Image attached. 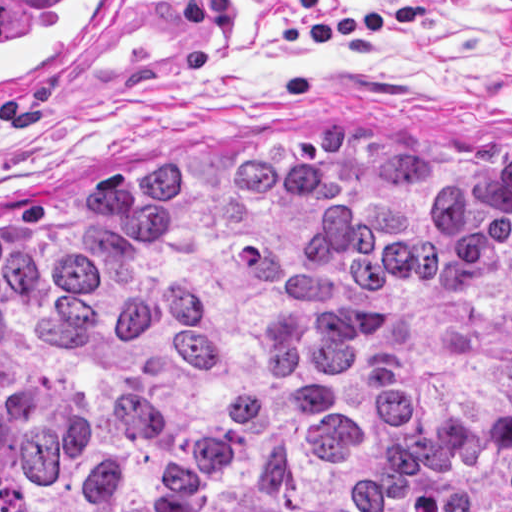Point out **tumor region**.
<instances>
[{"mask_svg":"<svg viewBox=\"0 0 512 512\" xmlns=\"http://www.w3.org/2000/svg\"><path fill=\"white\" fill-rule=\"evenodd\" d=\"M0 234V512H512V159L137 154Z\"/></svg>","mask_w":512,"mask_h":512,"instance_id":"tumor-region-1","label":"tumor region"}]
</instances>
